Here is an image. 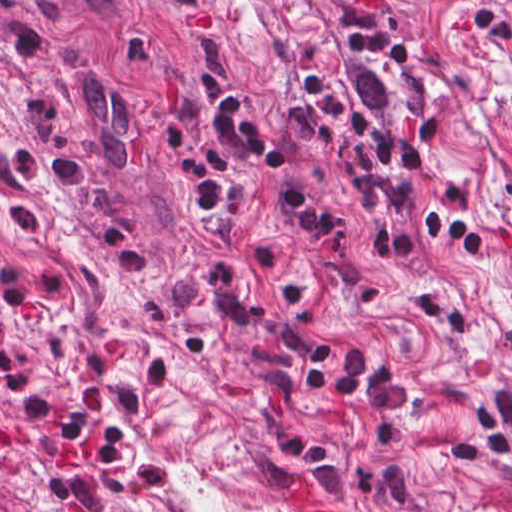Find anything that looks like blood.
I'll use <instances>...</instances> for the list:
<instances>
[{
	"mask_svg": "<svg viewBox=\"0 0 512 512\" xmlns=\"http://www.w3.org/2000/svg\"><path fill=\"white\" fill-rule=\"evenodd\" d=\"M285 507L288 512H312L309 474L299 473L293 490L285 495Z\"/></svg>",
	"mask_w": 512,
	"mask_h": 512,
	"instance_id": "1a1defca",
	"label": "blood"
}]
</instances>
